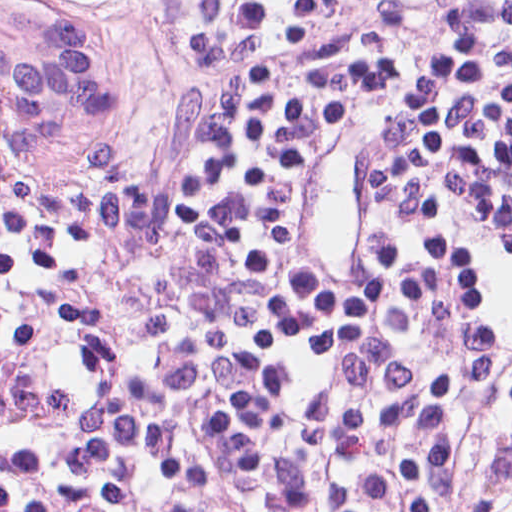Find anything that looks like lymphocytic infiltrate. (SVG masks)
<instances>
[{"instance_id": "lymphocytic-infiltrate-1", "label": "lymphocytic infiltrate", "mask_w": 512, "mask_h": 512, "mask_svg": "<svg viewBox=\"0 0 512 512\" xmlns=\"http://www.w3.org/2000/svg\"><path fill=\"white\" fill-rule=\"evenodd\" d=\"M147 60L142 114L85 189L0 147V215L83 249L167 239L213 202L255 78L325 64V104L268 229L251 351L282 448L357 449L431 371V512H512V0H99ZM66 174H87V168Z\"/></svg>"}]
</instances>
